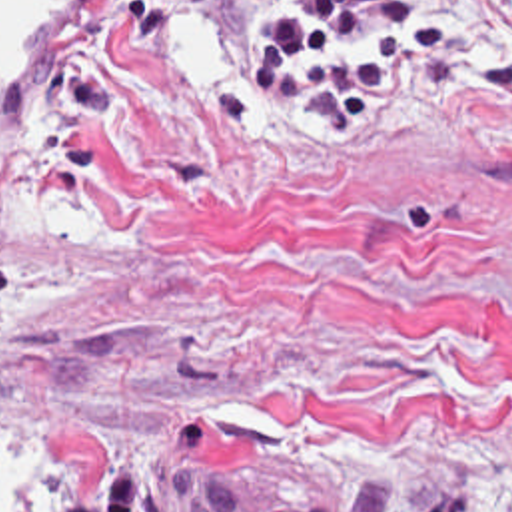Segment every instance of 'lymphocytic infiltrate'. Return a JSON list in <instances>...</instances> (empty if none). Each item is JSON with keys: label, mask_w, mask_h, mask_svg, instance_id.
<instances>
[{"label": "lymphocytic infiltrate", "mask_w": 512, "mask_h": 512, "mask_svg": "<svg viewBox=\"0 0 512 512\" xmlns=\"http://www.w3.org/2000/svg\"><path fill=\"white\" fill-rule=\"evenodd\" d=\"M415 53L393 0H291L287 29L239 79L253 121L337 127L383 103Z\"/></svg>", "instance_id": "lymphocytic-infiltrate-1"}]
</instances>
